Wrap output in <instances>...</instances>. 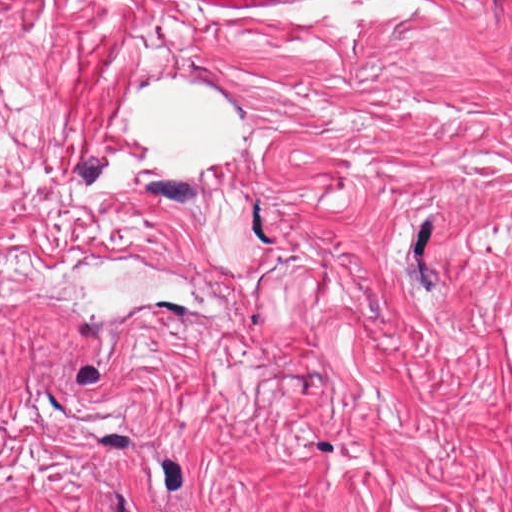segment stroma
Instances as JSON below:
<instances>
[{
  "label": "stroma",
  "mask_w": 512,
  "mask_h": 512,
  "mask_svg": "<svg viewBox=\"0 0 512 512\" xmlns=\"http://www.w3.org/2000/svg\"><path fill=\"white\" fill-rule=\"evenodd\" d=\"M0 512H512V0H0Z\"/></svg>",
  "instance_id": "1"
}]
</instances>
